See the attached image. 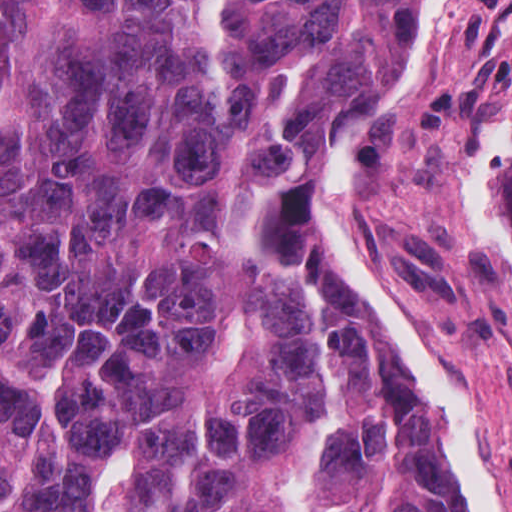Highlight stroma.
<instances>
[{"mask_svg": "<svg viewBox=\"0 0 512 512\" xmlns=\"http://www.w3.org/2000/svg\"><path fill=\"white\" fill-rule=\"evenodd\" d=\"M511 137L512 0H436L404 90L357 134L333 215L471 432L498 512H512V243L492 223V186ZM459 494L475 512L461 465Z\"/></svg>", "mask_w": 512, "mask_h": 512, "instance_id": "35a3bbf8", "label": "stroma"}]
</instances>
